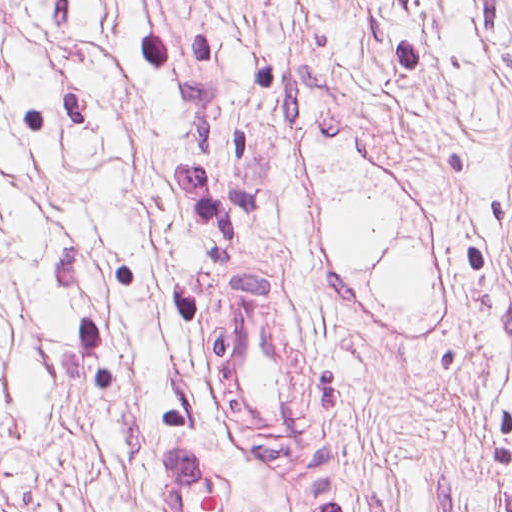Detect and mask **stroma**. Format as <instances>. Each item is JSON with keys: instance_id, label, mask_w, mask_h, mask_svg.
I'll return each instance as SVG.
<instances>
[{"instance_id": "stroma-1", "label": "stroma", "mask_w": 512, "mask_h": 512, "mask_svg": "<svg viewBox=\"0 0 512 512\" xmlns=\"http://www.w3.org/2000/svg\"><path fill=\"white\" fill-rule=\"evenodd\" d=\"M399 226L362 263L345 196ZM418 306L380 297L400 245ZM331 349L316 461L268 459L213 353L219 264ZM149 437L201 443L239 512H512V214L0 105V512H170Z\"/></svg>"}]
</instances>
